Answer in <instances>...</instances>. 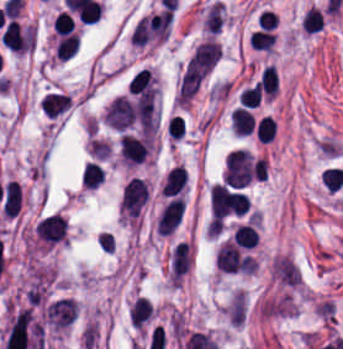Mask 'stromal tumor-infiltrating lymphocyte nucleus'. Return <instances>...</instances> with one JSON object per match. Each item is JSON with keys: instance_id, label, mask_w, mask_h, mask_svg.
Returning <instances> with one entry per match:
<instances>
[{"instance_id": "stromal-tumor-infiltrating-lymphocyte-nucleus-1", "label": "stromal tumor-infiltrating lymphocyte nucleus", "mask_w": 343, "mask_h": 349, "mask_svg": "<svg viewBox=\"0 0 343 349\" xmlns=\"http://www.w3.org/2000/svg\"><path fill=\"white\" fill-rule=\"evenodd\" d=\"M34 28L28 23L10 19L0 37L1 42L16 53H25L33 44Z\"/></svg>"}, {"instance_id": "stromal-tumor-infiltrating-lymphocyte-nucleus-2", "label": "stromal tumor-infiltrating lymphocyte nucleus", "mask_w": 343, "mask_h": 349, "mask_svg": "<svg viewBox=\"0 0 343 349\" xmlns=\"http://www.w3.org/2000/svg\"><path fill=\"white\" fill-rule=\"evenodd\" d=\"M148 198L145 182L138 176H131L125 183L119 208L130 217H137Z\"/></svg>"}, {"instance_id": "stromal-tumor-infiltrating-lymphocyte-nucleus-3", "label": "stromal tumor-infiltrating lymphocyte nucleus", "mask_w": 343, "mask_h": 349, "mask_svg": "<svg viewBox=\"0 0 343 349\" xmlns=\"http://www.w3.org/2000/svg\"><path fill=\"white\" fill-rule=\"evenodd\" d=\"M68 222L59 213H52L36 223L37 237L46 245L64 241Z\"/></svg>"}, {"instance_id": "stromal-tumor-infiltrating-lymphocyte-nucleus-4", "label": "stromal tumor-infiltrating lymphocyte nucleus", "mask_w": 343, "mask_h": 349, "mask_svg": "<svg viewBox=\"0 0 343 349\" xmlns=\"http://www.w3.org/2000/svg\"><path fill=\"white\" fill-rule=\"evenodd\" d=\"M38 104L43 116L58 118L69 109V92L53 87L43 92Z\"/></svg>"}, {"instance_id": "stromal-tumor-infiltrating-lymphocyte-nucleus-5", "label": "stromal tumor-infiltrating lymphocyte nucleus", "mask_w": 343, "mask_h": 349, "mask_svg": "<svg viewBox=\"0 0 343 349\" xmlns=\"http://www.w3.org/2000/svg\"><path fill=\"white\" fill-rule=\"evenodd\" d=\"M184 197L172 196L162 207L158 215L159 234H170L181 220Z\"/></svg>"}, {"instance_id": "stromal-tumor-infiltrating-lymphocyte-nucleus-6", "label": "stromal tumor-infiltrating lymphocyte nucleus", "mask_w": 343, "mask_h": 349, "mask_svg": "<svg viewBox=\"0 0 343 349\" xmlns=\"http://www.w3.org/2000/svg\"><path fill=\"white\" fill-rule=\"evenodd\" d=\"M152 302L143 295H136L127 307V319L132 327L144 329L153 319Z\"/></svg>"}, {"instance_id": "stromal-tumor-infiltrating-lymphocyte-nucleus-7", "label": "stromal tumor-infiltrating lymphocyte nucleus", "mask_w": 343, "mask_h": 349, "mask_svg": "<svg viewBox=\"0 0 343 349\" xmlns=\"http://www.w3.org/2000/svg\"><path fill=\"white\" fill-rule=\"evenodd\" d=\"M21 206V187L15 180H8L1 187V207L4 214L14 216Z\"/></svg>"}, {"instance_id": "stromal-tumor-infiltrating-lymphocyte-nucleus-8", "label": "stromal tumor-infiltrating lymphocyte nucleus", "mask_w": 343, "mask_h": 349, "mask_svg": "<svg viewBox=\"0 0 343 349\" xmlns=\"http://www.w3.org/2000/svg\"><path fill=\"white\" fill-rule=\"evenodd\" d=\"M186 174L185 169L180 165H173L165 174L161 193L163 195H171L179 189L185 187Z\"/></svg>"}, {"instance_id": "stromal-tumor-infiltrating-lymphocyte-nucleus-9", "label": "stromal tumor-infiltrating lymphocyte nucleus", "mask_w": 343, "mask_h": 349, "mask_svg": "<svg viewBox=\"0 0 343 349\" xmlns=\"http://www.w3.org/2000/svg\"><path fill=\"white\" fill-rule=\"evenodd\" d=\"M233 133L248 134L254 127L252 112L243 106H236L230 115Z\"/></svg>"}, {"instance_id": "stromal-tumor-infiltrating-lymphocyte-nucleus-10", "label": "stromal tumor-infiltrating lymphocyte nucleus", "mask_w": 343, "mask_h": 349, "mask_svg": "<svg viewBox=\"0 0 343 349\" xmlns=\"http://www.w3.org/2000/svg\"><path fill=\"white\" fill-rule=\"evenodd\" d=\"M232 237L242 248H252L259 240L257 227L250 221L238 223Z\"/></svg>"}, {"instance_id": "stromal-tumor-infiltrating-lymphocyte-nucleus-11", "label": "stromal tumor-infiltrating lymphocyte nucleus", "mask_w": 343, "mask_h": 349, "mask_svg": "<svg viewBox=\"0 0 343 349\" xmlns=\"http://www.w3.org/2000/svg\"><path fill=\"white\" fill-rule=\"evenodd\" d=\"M79 41L78 31L63 33L57 38L54 49L58 59H66L75 53Z\"/></svg>"}, {"instance_id": "stromal-tumor-infiltrating-lymphocyte-nucleus-12", "label": "stromal tumor-infiltrating lymphocyte nucleus", "mask_w": 343, "mask_h": 349, "mask_svg": "<svg viewBox=\"0 0 343 349\" xmlns=\"http://www.w3.org/2000/svg\"><path fill=\"white\" fill-rule=\"evenodd\" d=\"M259 87L264 97L270 100L278 92L276 72L271 65H264L260 71Z\"/></svg>"}, {"instance_id": "stromal-tumor-infiltrating-lymphocyte-nucleus-13", "label": "stromal tumor-infiltrating lymphocyte nucleus", "mask_w": 343, "mask_h": 349, "mask_svg": "<svg viewBox=\"0 0 343 349\" xmlns=\"http://www.w3.org/2000/svg\"><path fill=\"white\" fill-rule=\"evenodd\" d=\"M80 177L87 187H96L104 180V172L100 164L94 160H87L83 165Z\"/></svg>"}, {"instance_id": "stromal-tumor-infiltrating-lymphocyte-nucleus-14", "label": "stromal tumor-infiltrating lymphocyte nucleus", "mask_w": 343, "mask_h": 349, "mask_svg": "<svg viewBox=\"0 0 343 349\" xmlns=\"http://www.w3.org/2000/svg\"><path fill=\"white\" fill-rule=\"evenodd\" d=\"M322 24L323 15L319 8L313 5L304 12L300 20V27L304 32H317Z\"/></svg>"}, {"instance_id": "stromal-tumor-infiltrating-lymphocyte-nucleus-15", "label": "stromal tumor-infiltrating lymphocyte nucleus", "mask_w": 343, "mask_h": 349, "mask_svg": "<svg viewBox=\"0 0 343 349\" xmlns=\"http://www.w3.org/2000/svg\"><path fill=\"white\" fill-rule=\"evenodd\" d=\"M249 40L254 49L269 50L275 40V34L273 31L257 28L253 29L249 33Z\"/></svg>"}, {"instance_id": "stromal-tumor-infiltrating-lymphocyte-nucleus-16", "label": "stromal tumor-infiltrating lymphocyte nucleus", "mask_w": 343, "mask_h": 349, "mask_svg": "<svg viewBox=\"0 0 343 349\" xmlns=\"http://www.w3.org/2000/svg\"><path fill=\"white\" fill-rule=\"evenodd\" d=\"M260 90L258 84L254 81L238 91V105L244 107H253L258 105Z\"/></svg>"}, {"instance_id": "stromal-tumor-infiltrating-lymphocyte-nucleus-17", "label": "stromal tumor-infiltrating lymphocyte nucleus", "mask_w": 343, "mask_h": 349, "mask_svg": "<svg viewBox=\"0 0 343 349\" xmlns=\"http://www.w3.org/2000/svg\"><path fill=\"white\" fill-rule=\"evenodd\" d=\"M275 130V121L270 115H263L258 118L254 126L256 138L270 141Z\"/></svg>"}]
</instances>
